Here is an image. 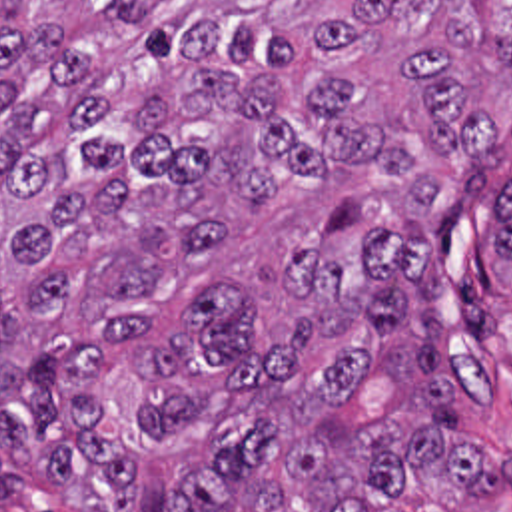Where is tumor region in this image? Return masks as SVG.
Instances as JSON below:
<instances>
[{"label": "tumor region", "instance_id": "obj_1", "mask_svg": "<svg viewBox=\"0 0 512 512\" xmlns=\"http://www.w3.org/2000/svg\"><path fill=\"white\" fill-rule=\"evenodd\" d=\"M511 157L512 0H0V496L509 490L461 436L447 275Z\"/></svg>", "mask_w": 512, "mask_h": 512}]
</instances>
